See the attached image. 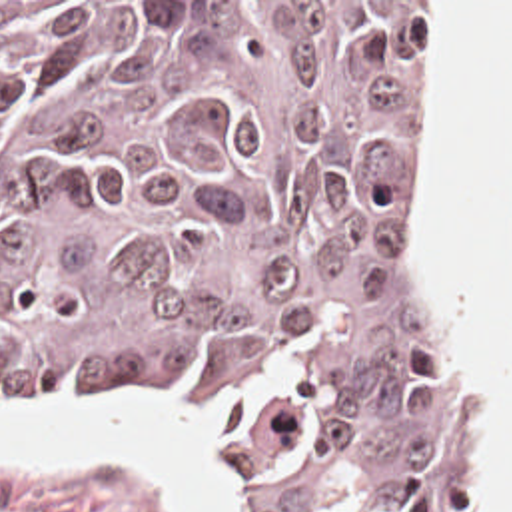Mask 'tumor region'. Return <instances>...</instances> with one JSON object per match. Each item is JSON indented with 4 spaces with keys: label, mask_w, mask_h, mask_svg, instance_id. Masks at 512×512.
Here are the masks:
<instances>
[{
    "label": "tumor region",
    "mask_w": 512,
    "mask_h": 512,
    "mask_svg": "<svg viewBox=\"0 0 512 512\" xmlns=\"http://www.w3.org/2000/svg\"><path fill=\"white\" fill-rule=\"evenodd\" d=\"M419 2H0V399L168 383L253 512H459L387 140Z\"/></svg>",
    "instance_id": "1"
}]
</instances>
